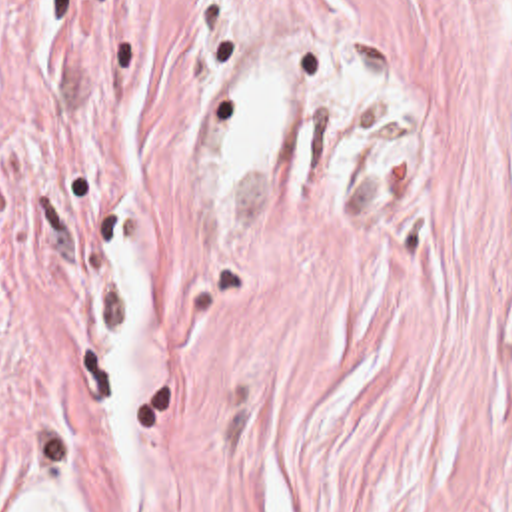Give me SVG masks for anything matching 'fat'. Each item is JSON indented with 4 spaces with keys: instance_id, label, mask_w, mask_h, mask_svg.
<instances>
[{
    "instance_id": "53f6f03d",
    "label": "fat",
    "mask_w": 512,
    "mask_h": 512,
    "mask_svg": "<svg viewBox=\"0 0 512 512\" xmlns=\"http://www.w3.org/2000/svg\"><path fill=\"white\" fill-rule=\"evenodd\" d=\"M25 512H71L65 497L45 493L43 489L29 501Z\"/></svg>"
}]
</instances>
